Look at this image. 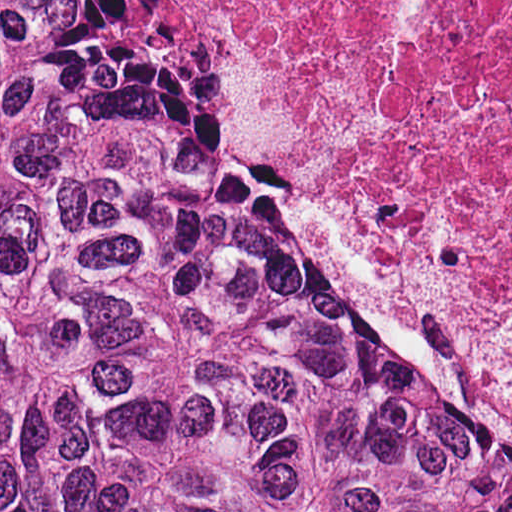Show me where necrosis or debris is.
<instances>
[{
	"instance_id": "1",
	"label": "necrosis or debris",
	"mask_w": 512,
	"mask_h": 512,
	"mask_svg": "<svg viewBox=\"0 0 512 512\" xmlns=\"http://www.w3.org/2000/svg\"><path fill=\"white\" fill-rule=\"evenodd\" d=\"M301 213L512 405V0H126Z\"/></svg>"
}]
</instances>
